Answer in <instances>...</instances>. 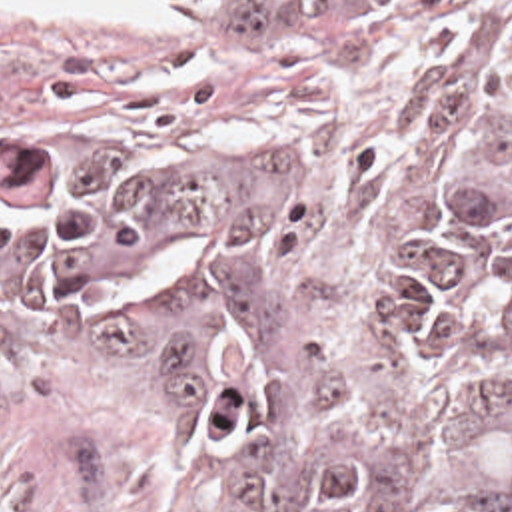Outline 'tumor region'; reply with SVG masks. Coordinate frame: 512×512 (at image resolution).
I'll return each mask as SVG.
<instances>
[{"mask_svg": "<svg viewBox=\"0 0 512 512\" xmlns=\"http://www.w3.org/2000/svg\"><path fill=\"white\" fill-rule=\"evenodd\" d=\"M178 2L372 20L412 0ZM0 276L97 340L258 512H512V188L430 192L368 316H340L260 154L47 144L0 182Z\"/></svg>", "mask_w": 512, "mask_h": 512, "instance_id": "obj_1", "label": "tumor region"}]
</instances>
